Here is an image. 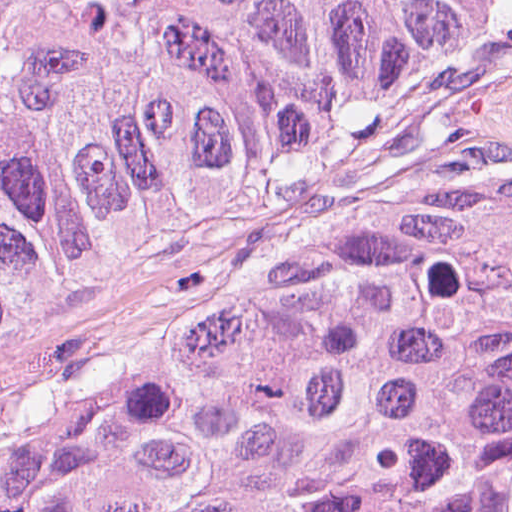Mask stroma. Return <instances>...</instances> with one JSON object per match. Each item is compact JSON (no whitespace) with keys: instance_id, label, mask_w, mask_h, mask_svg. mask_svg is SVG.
I'll return each mask as SVG.
<instances>
[{"instance_id":"35a3bbf8","label":"stroma","mask_w":512,"mask_h":512,"mask_svg":"<svg viewBox=\"0 0 512 512\" xmlns=\"http://www.w3.org/2000/svg\"><path fill=\"white\" fill-rule=\"evenodd\" d=\"M415 253H512V0L386 114L284 180L145 219L0 320V461L206 377L268 315Z\"/></svg>"}]
</instances>
